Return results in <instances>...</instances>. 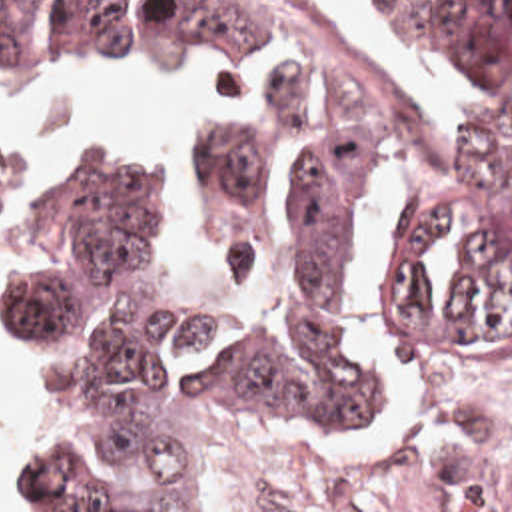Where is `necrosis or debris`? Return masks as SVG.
<instances>
[{"label": "necrosis or debris", "mask_w": 512, "mask_h": 512, "mask_svg": "<svg viewBox=\"0 0 512 512\" xmlns=\"http://www.w3.org/2000/svg\"><path fill=\"white\" fill-rule=\"evenodd\" d=\"M276 512H512V398H410L388 430L282 416L252 430Z\"/></svg>", "instance_id": "obj_1"}]
</instances>
